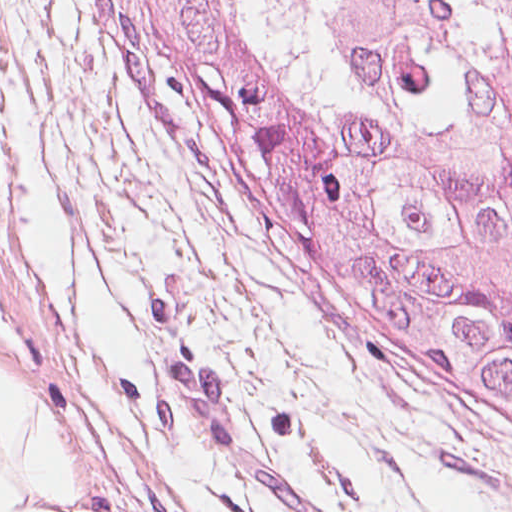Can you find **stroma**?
<instances>
[{"label": "stroma", "mask_w": 512, "mask_h": 512, "mask_svg": "<svg viewBox=\"0 0 512 512\" xmlns=\"http://www.w3.org/2000/svg\"><path fill=\"white\" fill-rule=\"evenodd\" d=\"M0 161L246 214L127 73L96 0H0Z\"/></svg>", "instance_id": "obj_1"}]
</instances>
